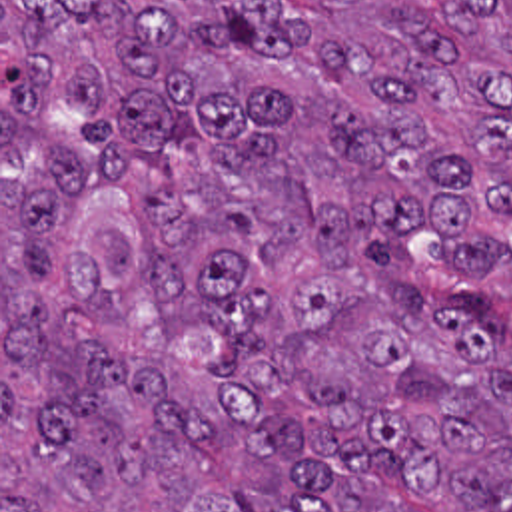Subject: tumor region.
Wrapping results in <instances>:
<instances>
[{
	"label": "tumor region",
	"mask_w": 512,
	"mask_h": 512,
	"mask_svg": "<svg viewBox=\"0 0 512 512\" xmlns=\"http://www.w3.org/2000/svg\"><path fill=\"white\" fill-rule=\"evenodd\" d=\"M0 512H512V0H0Z\"/></svg>",
	"instance_id": "obj_1"
}]
</instances>
